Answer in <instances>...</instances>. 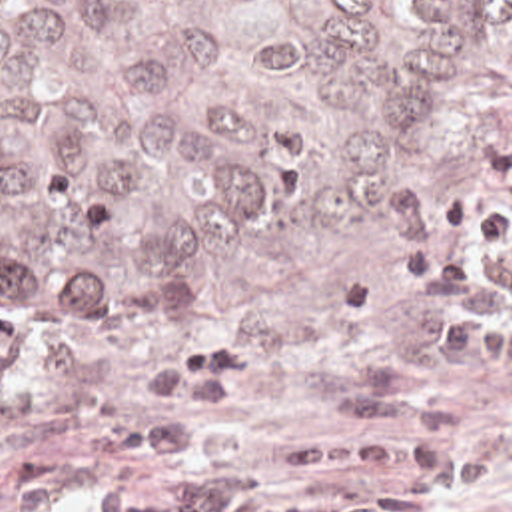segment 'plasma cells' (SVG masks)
<instances>
[{
  "label": "plasma cells",
  "mask_w": 512,
  "mask_h": 512,
  "mask_svg": "<svg viewBox=\"0 0 512 512\" xmlns=\"http://www.w3.org/2000/svg\"><path fill=\"white\" fill-rule=\"evenodd\" d=\"M401 301L429 347L449 353L407 433L327 445L273 473L215 475L199 439L253 359L241 347L181 349L143 369L147 393L163 399L135 423L149 469L89 491L85 512H441L485 485L487 441L453 411L481 371L512 367V93L485 153L401 261Z\"/></svg>",
  "instance_id": "plasma-cells-1"
}]
</instances>
